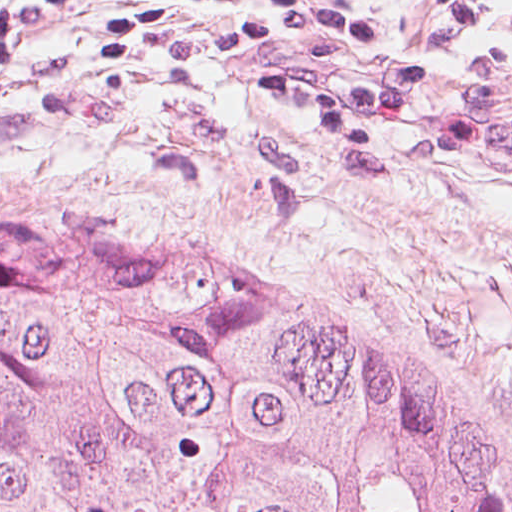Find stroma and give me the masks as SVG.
Instances as JSON below:
<instances>
[{
  "instance_id": "obj_1",
  "label": "stroma",
  "mask_w": 512,
  "mask_h": 512,
  "mask_svg": "<svg viewBox=\"0 0 512 512\" xmlns=\"http://www.w3.org/2000/svg\"><path fill=\"white\" fill-rule=\"evenodd\" d=\"M370 1L421 58L512 83V0L474 32L433 0ZM90 17L0 69V206L204 244L439 373L512 475V134L476 142L486 173L318 161L336 159L316 131L249 94L272 55L223 56L221 33L188 13L123 66L85 61Z\"/></svg>"
}]
</instances>
